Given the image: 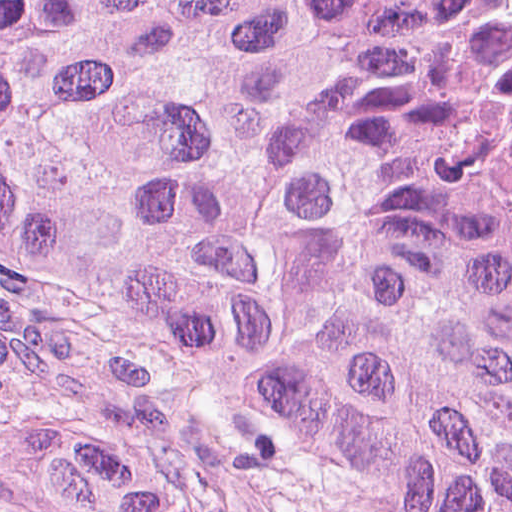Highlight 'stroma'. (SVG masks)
I'll list each match as a JSON object with an SVG mask.
<instances>
[{
	"mask_svg": "<svg viewBox=\"0 0 512 512\" xmlns=\"http://www.w3.org/2000/svg\"><path fill=\"white\" fill-rule=\"evenodd\" d=\"M0 512H294L180 356L0 249Z\"/></svg>",
	"mask_w": 512,
	"mask_h": 512,
	"instance_id": "stroma-1",
	"label": "stroma"
}]
</instances>
